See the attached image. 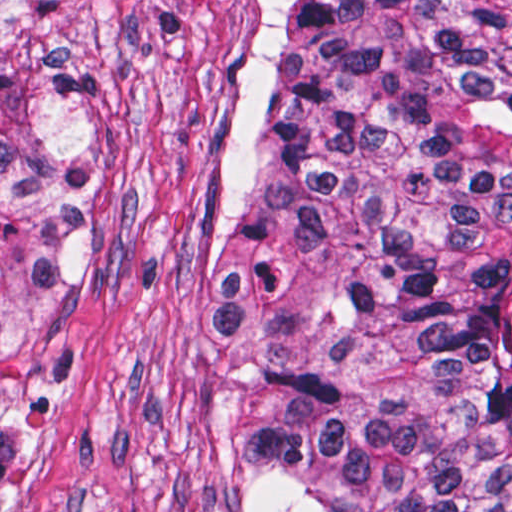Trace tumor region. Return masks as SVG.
Masks as SVG:
<instances>
[{"mask_svg":"<svg viewBox=\"0 0 512 512\" xmlns=\"http://www.w3.org/2000/svg\"><path fill=\"white\" fill-rule=\"evenodd\" d=\"M233 276L266 326L244 512H512V0H266ZM74 0H0V510L86 323Z\"/></svg>","mask_w":512,"mask_h":512,"instance_id":"e687c5a6","label":"tumor region"}]
</instances>
